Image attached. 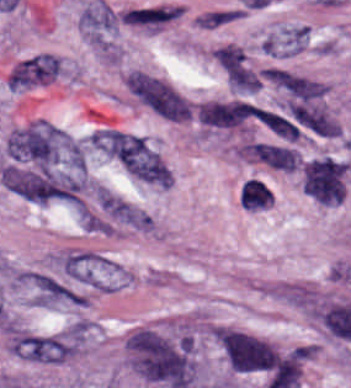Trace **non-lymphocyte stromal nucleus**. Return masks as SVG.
<instances>
[{"label":"non-lymphocyte stromal nucleus","instance_id":"obj_1","mask_svg":"<svg viewBox=\"0 0 351 388\" xmlns=\"http://www.w3.org/2000/svg\"><path fill=\"white\" fill-rule=\"evenodd\" d=\"M125 81L133 95L160 115L188 120L192 109L187 99L163 79L142 71H129Z\"/></svg>","mask_w":351,"mask_h":388},{"label":"non-lymphocyte stromal nucleus","instance_id":"obj_2","mask_svg":"<svg viewBox=\"0 0 351 388\" xmlns=\"http://www.w3.org/2000/svg\"><path fill=\"white\" fill-rule=\"evenodd\" d=\"M213 56L234 93L255 94L261 89L262 77L242 46L229 42Z\"/></svg>","mask_w":351,"mask_h":388},{"label":"non-lymphocyte stromal nucleus","instance_id":"obj_3","mask_svg":"<svg viewBox=\"0 0 351 388\" xmlns=\"http://www.w3.org/2000/svg\"><path fill=\"white\" fill-rule=\"evenodd\" d=\"M120 161L125 172L136 179L169 187V170L166 164L142 136H134Z\"/></svg>","mask_w":351,"mask_h":388},{"label":"non-lymphocyte stromal nucleus","instance_id":"obj_4","mask_svg":"<svg viewBox=\"0 0 351 388\" xmlns=\"http://www.w3.org/2000/svg\"><path fill=\"white\" fill-rule=\"evenodd\" d=\"M176 19L173 5H141L124 10L123 22L130 26L158 30Z\"/></svg>","mask_w":351,"mask_h":388},{"label":"non-lymphocyte stromal nucleus","instance_id":"obj_5","mask_svg":"<svg viewBox=\"0 0 351 388\" xmlns=\"http://www.w3.org/2000/svg\"><path fill=\"white\" fill-rule=\"evenodd\" d=\"M270 76L276 84L302 100L319 98L327 90L319 82L284 71H271Z\"/></svg>","mask_w":351,"mask_h":388},{"label":"non-lymphocyte stromal nucleus","instance_id":"obj_6","mask_svg":"<svg viewBox=\"0 0 351 388\" xmlns=\"http://www.w3.org/2000/svg\"><path fill=\"white\" fill-rule=\"evenodd\" d=\"M254 154L273 168L293 172L297 167L298 153L289 147L255 142Z\"/></svg>","mask_w":351,"mask_h":388},{"label":"non-lymphocyte stromal nucleus","instance_id":"obj_7","mask_svg":"<svg viewBox=\"0 0 351 388\" xmlns=\"http://www.w3.org/2000/svg\"><path fill=\"white\" fill-rule=\"evenodd\" d=\"M240 200L245 209L257 210L273 204L274 196L267 184L251 178L242 187Z\"/></svg>","mask_w":351,"mask_h":388},{"label":"non-lymphocyte stromal nucleus","instance_id":"obj_8","mask_svg":"<svg viewBox=\"0 0 351 388\" xmlns=\"http://www.w3.org/2000/svg\"><path fill=\"white\" fill-rule=\"evenodd\" d=\"M262 122L277 135L289 140L297 141L299 130L297 125L287 120L281 115L271 113L261 109Z\"/></svg>","mask_w":351,"mask_h":388}]
</instances>
